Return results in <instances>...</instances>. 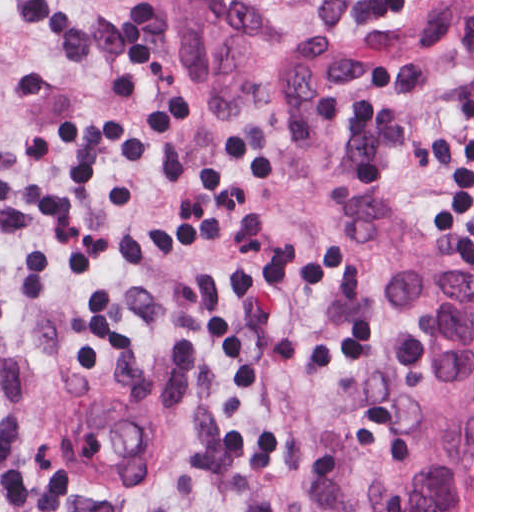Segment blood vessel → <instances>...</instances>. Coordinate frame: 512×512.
I'll list each match as a JSON object with an SVG mask.
<instances>
[{"mask_svg": "<svg viewBox=\"0 0 512 512\" xmlns=\"http://www.w3.org/2000/svg\"><path fill=\"white\" fill-rule=\"evenodd\" d=\"M185 452L186 427L174 410L110 388L72 393L48 434L52 466L112 498L167 485Z\"/></svg>", "mask_w": 512, "mask_h": 512, "instance_id": "1", "label": "blood vessel"}]
</instances>
